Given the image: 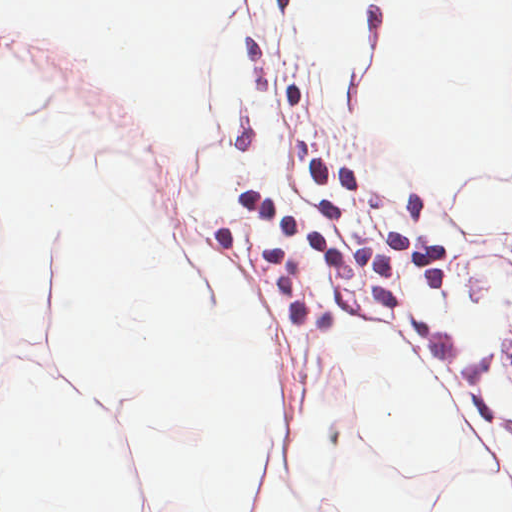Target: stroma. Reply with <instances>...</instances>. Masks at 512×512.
Returning a JSON list of instances; mask_svg holds the SVG:
<instances>
[{
  "label": "stroma",
  "instance_id": "stroma-1",
  "mask_svg": "<svg viewBox=\"0 0 512 512\" xmlns=\"http://www.w3.org/2000/svg\"><path fill=\"white\" fill-rule=\"evenodd\" d=\"M316 0H226L201 41L195 85L211 125L163 141L118 85L105 154L153 184L185 253L251 278L289 358L263 444L253 512H323L316 492L340 446L427 490L438 512L478 472L512 496V224L441 204L382 94L401 31L398 0H357L364 52L329 72L309 34ZM512 52V49L510 53ZM392 331L424 365L457 450L425 475L389 465L354 404L351 354ZM91 400L137 481L136 512H173L169 482L117 392L58 368Z\"/></svg>",
  "mask_w": 512,
  "mask_h": 512
}]
</instances>
